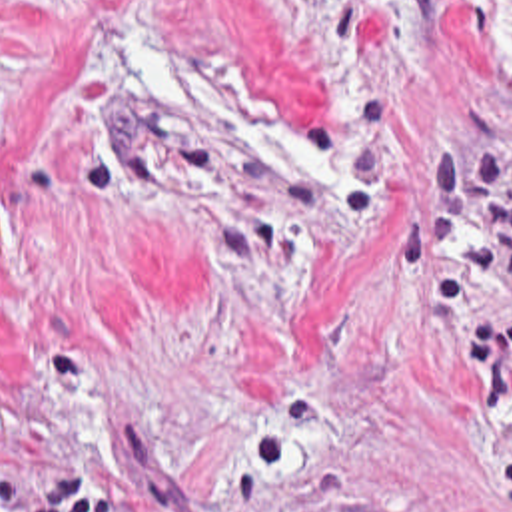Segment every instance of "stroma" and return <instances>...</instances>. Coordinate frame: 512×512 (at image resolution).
I'll return each instance as SVG.
<instances>
[{"label":"stroma","mask_w":512,"mask_h":512,"mask_svg":"<svg viewBox=\"0 0 512 512\" xmlns=\"http://www.w3.org/2000/svg\"><path fill=\"white\" fill-rule=\"evenodd\" d=\"M127 512H512V0H0V476Z\"/></svg>","instance_id":"1"}]
</instances>
